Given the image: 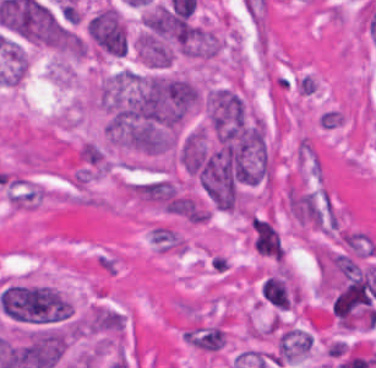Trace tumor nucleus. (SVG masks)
<instances>
[{"label": "tumor nucleus", "mask_w": 376, "mask_h": 368, "mask_svg": "<svg viewBox=\"0 0 376 368\" xmlns=\"http://www.w3.org/2000/svg\"><path fill=\"white\" fill-rule=\"evenodd\" d=\"M83 31L87 45L99 56L118 58L129 44L124 16L107 2L85 20Z\"/></svg>", "instance_id": "tumor-nucleus-1"}, {"label": "tumor nucleus", "mask_w": 376, "mask_h": 368, "mask_svg": "<svg viewBox=\"0 0 376 368\" xmlns=\"http://www.w3.org/2000/svg\"><path fill=\"white\" fill-rule=\"evenodd\" d=\"M204 105L208 125L216 136H234L248 123L244 99L237 88H211Z\"/></svg>", "instance_id": "tumor-nucleus-2"}]
</instances>
